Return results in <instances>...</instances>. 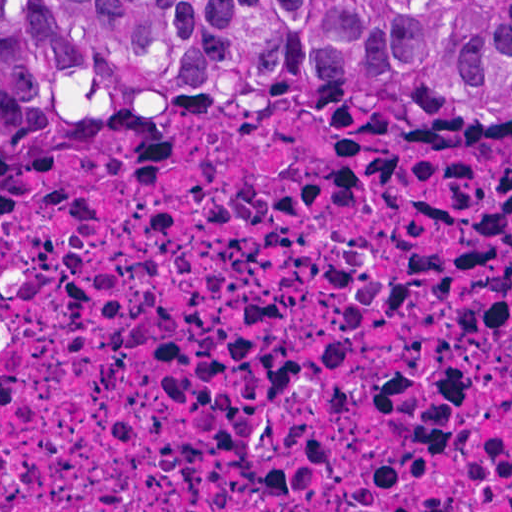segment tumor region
Returning <instances> with one entry per match:
<instances>
[{"label":"tumor region","mask_w":512,"mask_h":512,"mask_svg":"<svg viewBox=\"0 0 512 512\" xmlns=\"http://www.w3.org/2000/svg\"><path fill=\"white\" fill-rule=\"evenodd\" d=\"M104 119L512 126V0H0V185Z\"/></svg>","instance_id":"obj_1"}]
</instances>
